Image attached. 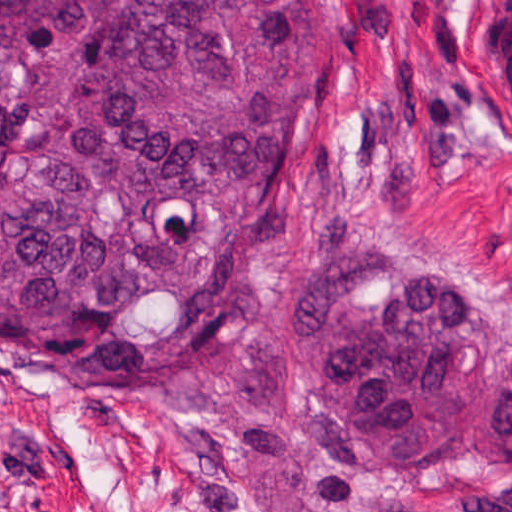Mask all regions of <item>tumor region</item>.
I'll return each mask as SVG.
<instances>
[{
  "instance_id": "e687c5a6",
  "label": "tumor region",
  "mask_w": 512,
  "mask_h": 512,
  "mask_svg": "<svg viewBox=\"0 0 512 512\" xmlns=\"http://www.w3.org/2000/svg\"><path fill=\"white\" fill-rule=\"evenodd\" d=\"M314 109L302 0H0V353L154 405L260 504L512 484V297L399 226L316 244L230 339L218 290Z\"/></svg>"
}]
</instances>
